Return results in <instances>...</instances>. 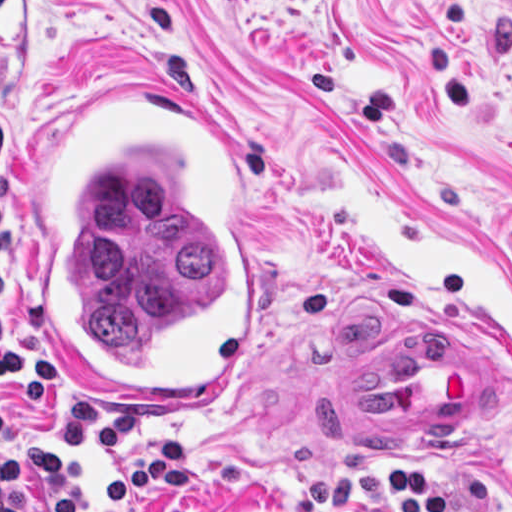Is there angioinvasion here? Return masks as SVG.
Wrapping results in <instances>:
<instances>
[{"mask_svg":"<svg viewBox=\"0 0 512 512\" xmlns=\"http://www.w3.org/2000/svg\"><path fill=\"white\" fill-rule=\"evenodd\" d=\"M152 80L63 109L40 145L33 330L83 401L209 407L263 334V183Z\"/></svg>","mask_w":512,"mask_h":512,"instance_id":"obj_1","label":"angioinvasion"}]
</instances>
